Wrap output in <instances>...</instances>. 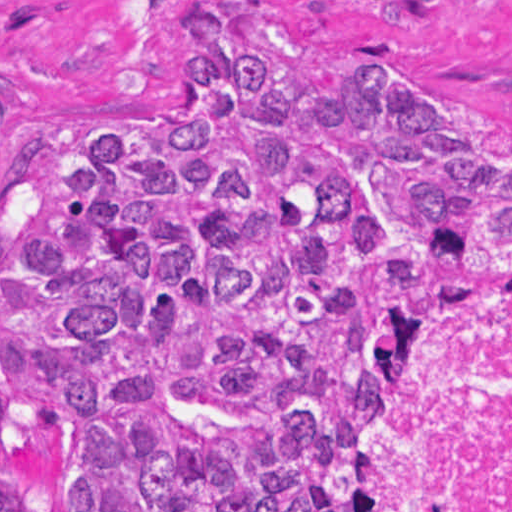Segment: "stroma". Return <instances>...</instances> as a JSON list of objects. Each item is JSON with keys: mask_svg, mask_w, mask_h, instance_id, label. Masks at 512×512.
<instances>
[{"mask_svg": "<svg viewBox=\"0 0 512 512\" xmlns=\"http://www.w3.org/2000/svg\"><path fill=\"white\" fill-rule=\"evenodd\" d=\"M190 0H0V134L174 123L194 64L147 19ZM321 61H364L407 108L512 146V0H232Z\"/></svg>", "mask_w": 512, "mask_h": 512, "instance_id": "obj_1", "label": "stroma"}]
</instances>
